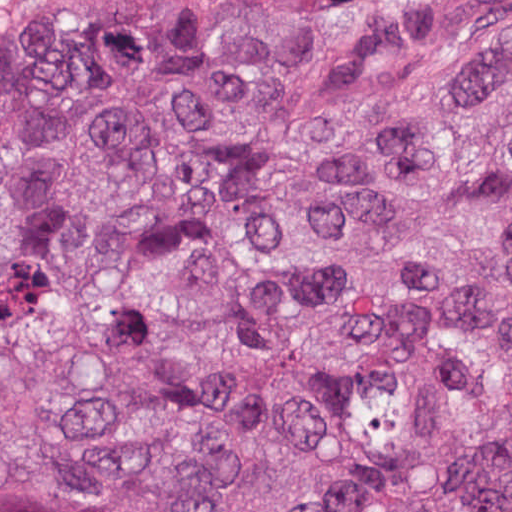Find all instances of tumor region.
Listing matches in <instances>:
<instances>
[{
    "label": "tumor region",
    "mask_w": 512,
    "mask_h": 512,
    "mask_svg": "<svg viewBox=\"0 0 512 512\" xmlns=\"http://www.w3.org/2000/svg\"><path fill=\"white\" fill-rule=\"evenodd\" d=\"M0 512H512V0L0 8Z\"/></svg>",
    "instance_id": "e687c5a6"
}]
</instances>
